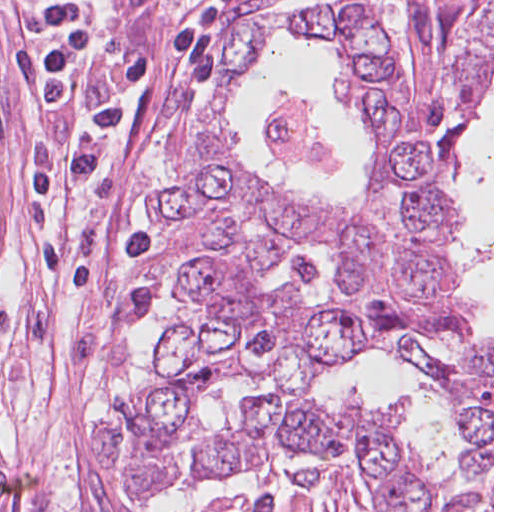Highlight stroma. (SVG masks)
Listing matches in <instances>:
<instances>
[{"mask_svg": "<svg viewBox=\"0 0 512 512\" xmlns=\"http://www.w3.org/2000/svg\"><path fill=\"white\" fill-rule=\"evenodd\" d=\"M161 387L36 0H0V460L10 512H201L95 460Z\"/></svg>", "mask_w": 512, "mask_h": 512, "instance_id": "1", "label": "stroma"}]
</instances>
